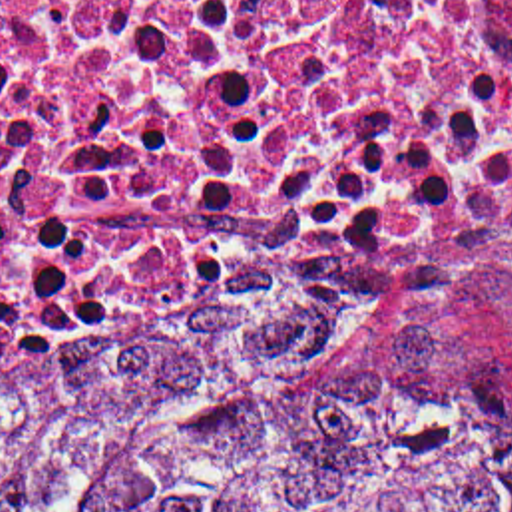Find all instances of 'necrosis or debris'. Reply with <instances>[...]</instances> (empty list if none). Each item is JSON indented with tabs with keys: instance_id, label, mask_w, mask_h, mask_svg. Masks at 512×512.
I'll use <instances>...</instances> for the list:
<instances>
[{
	"instance_id": "4bbe7bcc",
	"label": "necrosis or debris",
	"mask_w": 512,
	"mask_h": 512,
	"mask_svg": "<svg viewBox=\"0 0 512 512\" xmlns=\"http://www.w3.org/2000/svg\"><path fill=\"white\" fill-rule=\"evenodd\" d=\"M503 243L512 0H0V360L372 328Z\"/></svg>"
}]
</instances>
